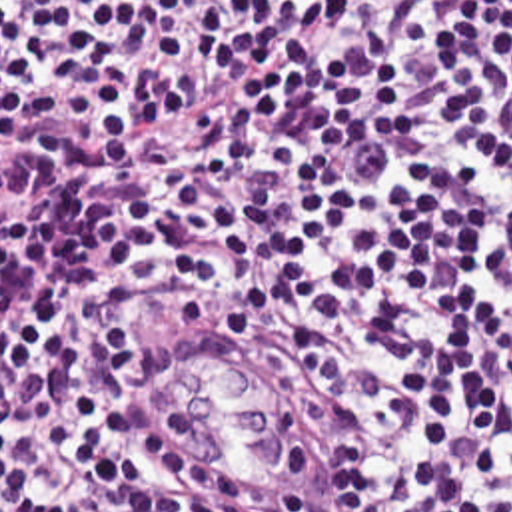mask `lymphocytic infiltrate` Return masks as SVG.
<instances>
[{"label": "lymphocytic infiltrate", "mask_w": 512, "mask_h": 512, "mask_svg": "<svg viewBox=\"0 0 512 512\" xmlns=\"http://www.w3.org/2000/svg\"><path fill=\"white\" fill-rule=\"evenodd\" d=\"M166 318L326 426L310 512H512V0H0V512H278Z\"/></svg>", "instance_id": "f902f5d3"}]
</instances>
